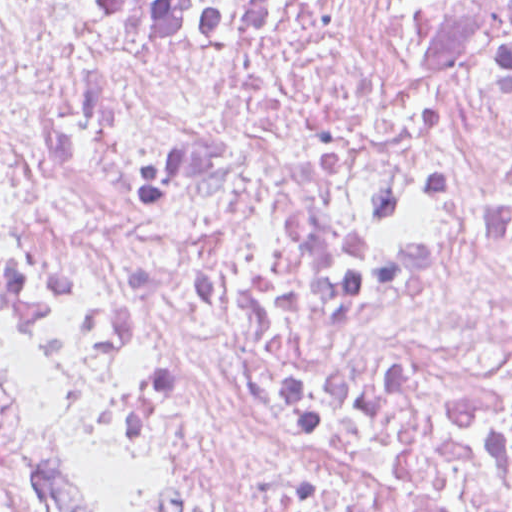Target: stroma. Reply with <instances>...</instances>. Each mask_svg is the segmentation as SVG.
<instances>
[{"label":"stroma","instance_id":"stroma-1","mask_svg":"<svg viewBox=\"0 0 512 512\" xmlns=\"http://www.w3.org/2000/svg\"><path fill=\"white\" fill-rule=\"evenodd\" d=\"M0 354L2 356L3 362L5 364L6 370L9 374L10 378L12 379V381L14 382V384L17 386V388L19 389V391L21 393L20 385H19L16 373H15V370H14V367H13V364H12V361H11V358H10V355H9V352H8V349H7V346H6L4 337H3L1 328H0ZM50 481H51L53 487L55 488L57 494L59 495L61 501L63 502L64 506L68 509L69 512H85L82 509H80L79 507H76L73 504H71L70 502H68L67 500H65L63 498V496L61 495V493L59 492V490L57 489V487L55 486V484L53 483V481L51 480V478H50Z\"/></svg>","mask_w":512,"mask_h":512}]
</instances>
